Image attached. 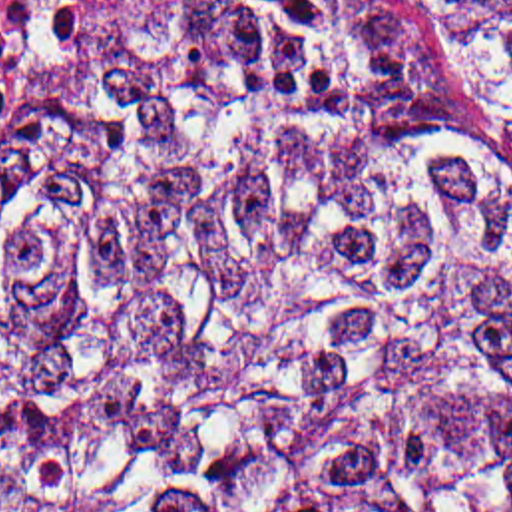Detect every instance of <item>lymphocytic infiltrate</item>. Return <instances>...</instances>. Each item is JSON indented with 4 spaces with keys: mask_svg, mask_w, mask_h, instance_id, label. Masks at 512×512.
Wrapping results in <instances>:
<instances>
[{
    "mask_svg": "<svg viewBox=\"0 0 512 512\" xmlns=\"http://www.w3.org/2000/svg\"><path fill=\"white\" fill-rule=\"evenodd\" d=\"M111 0H0V95Z\"/></svg>",
    "mask_w": 512,
    "mask_h": 512,
    "instance_id": "f902f5d3",
    "label": "lymphocytic infiltrate"
}]
</instances>
